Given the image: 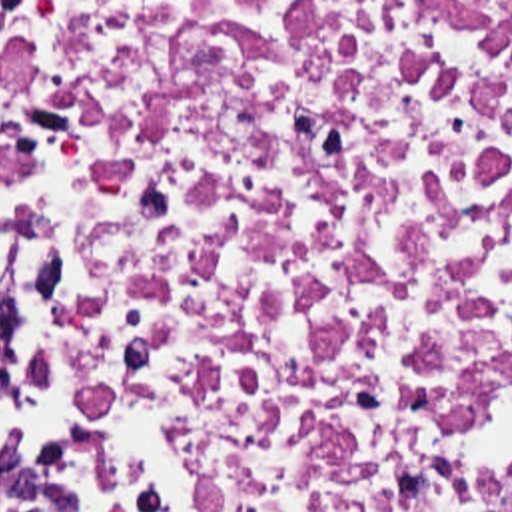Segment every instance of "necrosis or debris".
<instances>
[{
	"label": "necrosis or debris",
	"mask_w": 512,
	"mask_h": 512,
	"mask_svg": "<svg viewBox=\"0 0 512 512\" xmlns=\"http://www.w3.org/2000/svg\"><path fill=\"white\" fill-rule=\"evenodd\" d=\"M0 232L163 512H512V2H0Z\"/></svg>",
	"instance_id": "obj_1"
}]
</instances>
